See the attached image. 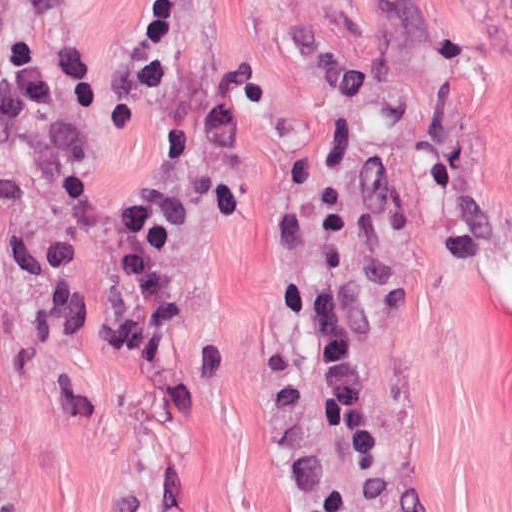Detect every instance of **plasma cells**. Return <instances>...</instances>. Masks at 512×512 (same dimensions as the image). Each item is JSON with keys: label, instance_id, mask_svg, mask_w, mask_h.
Segmentation results:
<instances>
[{"label": "plasma cells", "instance_id": "plasma-cells-1", "mask_svg": "<svg viewBox=\"0 0 512 512\" xmlns=\"http://www.w3.org/2000/svg\"><path fill=\"white\" fill-rule=\"evenodd\" d=\"M295 41L316 81L347 110H355L368 87L364 71L336 60L310 27L293 29ZM176 25L168 0L145 7L137 43V78L159 86L192 91L190 110L167 147L166 169L129 203L116 201L74 175L67 177L70 202L102 225L120 248L121 272L132 298L122 312L107 315L90 331L101 344L136 360H153L173 324L166 293L163 249L173 231L189 216L178 187L180 171L192 173L226 216L243 213L233 185L245 142V111L257 88L249 65L218 80L190 71L175 54ZM82 102L94 106L99 95L81 59L68 53L47 69L32 48L0 26V142L11 141L18 128L43 108ZM284 297L315 340L323 366L312 413L355 459L379 458V439L355 388L354 356L344 329L343 288L337 281L287 282ZM1 386V384H0Z\"/></svg>", "mask_w": 512, "mask_h": 512}]
</instances>
